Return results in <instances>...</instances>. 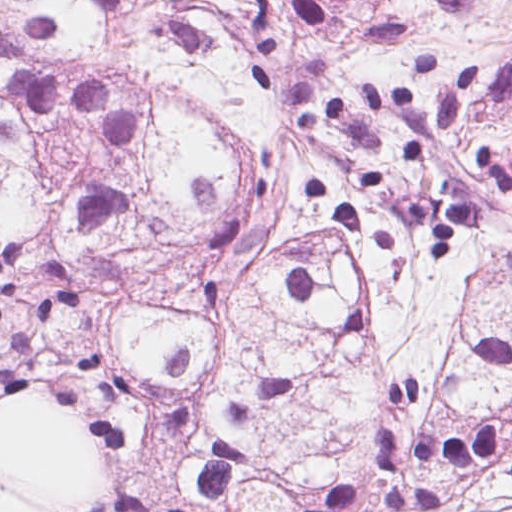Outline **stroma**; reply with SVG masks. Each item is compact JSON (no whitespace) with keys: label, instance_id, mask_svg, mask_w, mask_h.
<instances>
[{"label":"stroma","instance_id":"35a3bbf8","mask_svg":"<svg viewBox=\"0 0 512 512\" xmlns=\"http://www.w3.org/2000/svg\"><path fill=\"white\" fill-rule=\"evenodd\" d=\"M21 219L12 177L0 167V233ZM25 405L55 408L77 420L106 464V482L98 505L88 512H139L112 478L108 445L99 429L66 403L52 398L0 399V416ZM492 419L512 451V404H475L447 391L431 376L405 372L386 386L373 413L369 456L361 467L303 500L295 512L334 487L360 489L357 502L340 512H512V474L498 460L485 457L468 466H430L410 460L392 477L382 473L381 452L392 430L405 449L447 432L473 430ZM2 481L0 479V496Z\"/></svg>","mask_w":512,"mask_h":512}]
</instances>
